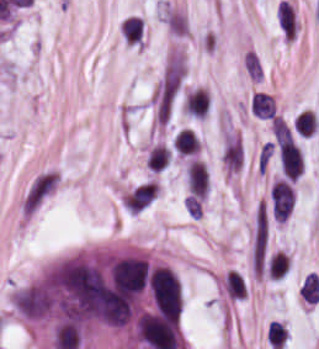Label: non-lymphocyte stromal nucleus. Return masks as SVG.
I'll list each match as a JSON object with an SVG mask.
<instances>
[{
	"mask_svg": "<svg viewBox=\"0 0 319 349\" xmlns=\"http://www.w3.org/2000/svg\"><path fill=\"white\" fill-rule=\"evenodd\" d=\"M61 177L52 167L37 171L18 199V209L23 216L33 214L57 189Z\"/></svg>",
	"mask_w": 319,
	"mask_h": 349,
	"instance_id": "dd21d789",
	"label": "non-lymphocyte stromal nucleus"
},
{
	"mask_svg": "<svg viewBox=\"0 0 319 349\" xmlns=\"http://www.w3.org/2000/svg\"><path fill=\"white\" fill-rule=\"evenodd\" d=\"M244 145L240 137L228 134L223 146V164L229 172H238L244 159Z\"/></svg>",
	"mask_w": 319,
	"mask_h": 349,
	"instance_id": "a72fc3eb",
	"label": "non-lymphocyte stromal nucleus"
},
{
	"mask_svg": "<svg viewBox=\"0 0 319 349\" xmlns=\"http://www.w3.org/2000/svg\"><path fill=\"white\" fill-rule=\"evenodd\" d=\"M172 158L169 146L161 142H153L146 150V164L151 172H160L165 168Z\"/></svg>",
	"mask_w": 319,
	"mask_h": 349,
	"instance_id": "3746e769",
	"label": "non-lymphocyte stromal nucleus"
},
{
	"mask_svg": "<svg viewBox=\"0 0 319 349\" xmlns=\"http://www.w3.org/2000/svg\"><path fill=\"white\" fill-rule=\"evenodd\" d=\"M274 142L279 147H293V135L282 115L271 117Z\"/></svg>",
	"mask_w": 319,
	"mask_h": 349,
	"instance_id": "fc2b8d12",
	"label": "non-lymphocyte stromal nucleus"
},
{
	"mask_svg": "<svg viewBox=\"0 0 319 349\" xmlns=\"http://www.w3.org/2000/svg\"><path fill=\"white\" fill-rule=\"evenodd\" d=\"M299 294L303 300L317 303L319 301V281L316 272H309L303 279Z\"/></svg>",
	"mask_w": 319,
	"mask_h": 349,
	"instance_id": "81446118",
	"label": "non-lymphocyte stromal nucleus"
},
{
	"mask_svg": "<svg viewBox=\"0 0 319 349\" xmlns=\"http://www.w3.org/2000/svg\"><path fill=\"white\" fill-rule=\"evenodd\" d=\"M226 292L230 297L241 298L246 295V286L236 270H229L225 275Z\"/></svg>",
	"mask_w": 319,
	"mask_h": 349,
	"instance_id": "7c5642bf",
	"label": "non-lymphocyte stromal nucleus"
}]
</instances>
